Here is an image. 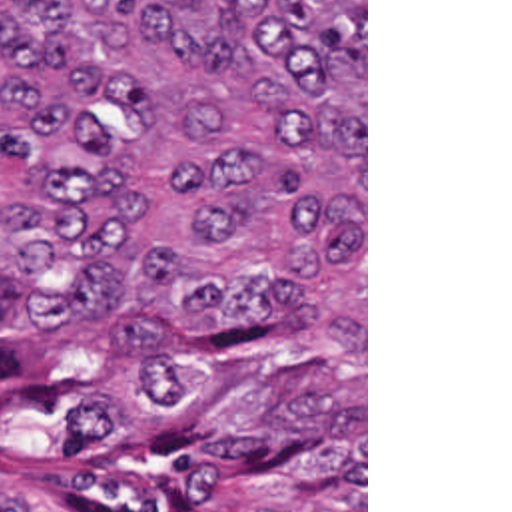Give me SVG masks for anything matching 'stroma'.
<instances>
[{
	"mask_svg": "<svg viewBox=\"0 0 512 512\" xmlns=\"http://www.w3.org/2000/svg\"><path fill=\"white\" fill-rule=\"evenodd\" d=\"M0 502H17L1 492ZM29 512H53L27 506ZM364 512H368V0H364Z\"/></svg>",
	"mask_w": 512,
	"mask_h": 512,
	"instance_id": "35a3bbf8",
	"label": "stroma"
}]
</instances>
